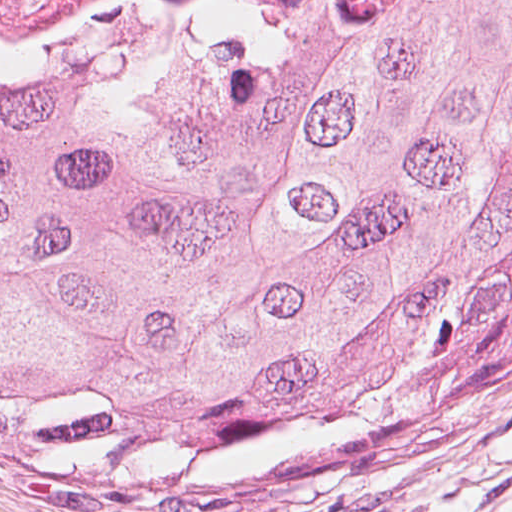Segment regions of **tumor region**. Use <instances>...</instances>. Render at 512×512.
Listing matches in <instances>:
<instances>
[{
  "mask_svg": "<svg viewBox=\"0 0 512 512\" xmlns=\"http://www.w3.org/2000/svg\"><path fill=\"white\" fill-rule=\"evenodd\" d=\"M231 26L0 43V410L136 479Z\"/></svg>",
  "mask_w": 512,
  "mask_h": 512,
  "instance_id": "tumor-region-1",
  "label": "tumor region"
}]
</instances>
